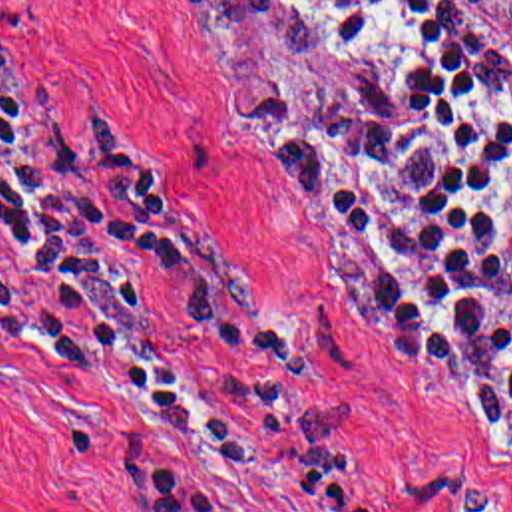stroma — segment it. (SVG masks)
<instances>
[{
	"label": "stroma",
	"instance_id": "obj_1",
	"mask_svg": "<svg viewBox=\"0 0 512 512\" xmlns=\"http://www.w3.org/2000/svg\"><path fill=\"white\" fill-rule=\"evenodd\" d=\"M441 1L512 61V0ZM348 87L312 47L175 0H0L7 111L41 133L59 101L101 121L185 208L202 246L280 312L342 433L346 491L396 512H512V422L499 424L461 372L386 344L314 216L212 125L224 101L338 103ZM117 256L191 382L228 420H254L175 288L147 260ZM129 459L193 475L218 512H330L296 495L282 441L274 463H214L41 352L0 342V512H125Z\"/></svg>",
	"mask_w": 512,
	"mask_h": 512
}]
</instances>
